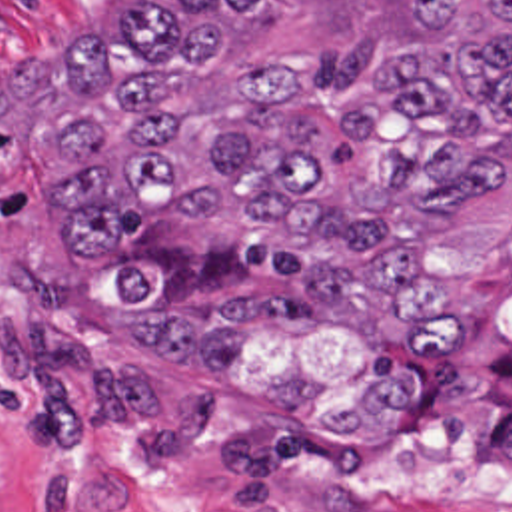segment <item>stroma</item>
Returning <instances> with one entry per match:
<instances>
[{
	"label": "stroma",
	"instance_id": "stroma-1",
	"mask_svg": "<svg viewBox=\"0 0 512 512\" xmlns=\"http://www.w3.org/2000/svg\"><path fill=\"white\" fill-rule=\"evenodd\" d=\"M129 0H0V512H512V180L437 236L431 274L459 298L449 338L421 340V397L389 447H179L129 403L107 348V266L163 216L137 206L99 254H75L45 182L61 44ZM413 0H265L217 64L171 78L193 120L263 52H307L347 94L387 58ZM481 34L489 0H469Z\"/></svg>",
	"mask_w": 512,
	"mask_h": 512
}]
</instances>
